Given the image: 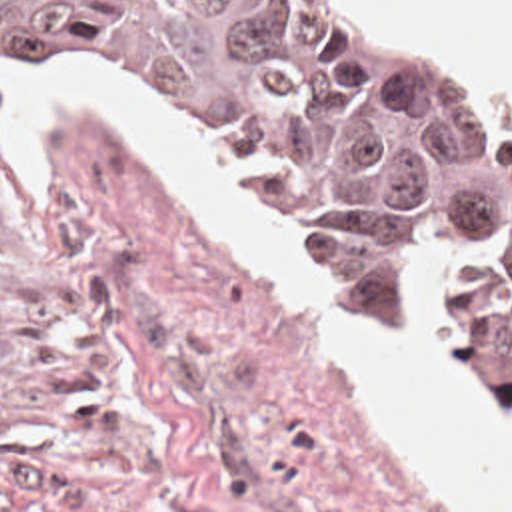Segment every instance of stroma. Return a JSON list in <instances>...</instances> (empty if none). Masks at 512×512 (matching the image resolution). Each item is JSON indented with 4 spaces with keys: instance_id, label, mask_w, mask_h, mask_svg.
Masks as SVG:
<instances>
[{
    "instance_id": "obj_1",
    "label": "stroma",
    "mask_w": 512,
    "mask_h": 512,
    "mask_svg": "<svg viewBox=\"0 0 512 512\" xmlns=\"http://www.w3.org/2000/svg\"><path fill=\"white\" fill-rule=\"evenodd\" d=\"M304 1L374 43L436 47L512 145L508 105L446 47L380 37L332 0ZM55 77L110 85L198 129L364 327L400 331L416 301L428 305L460 379L492 411L442 331L426 267L376 323L336 277L324 197L292 207L264 193L198 115L130 79L0 69V512H452L338 369L324 325L210 247L110 119L49 113L27 195L3 155L9 89Z\"/></svg>"
}]
</instances>
